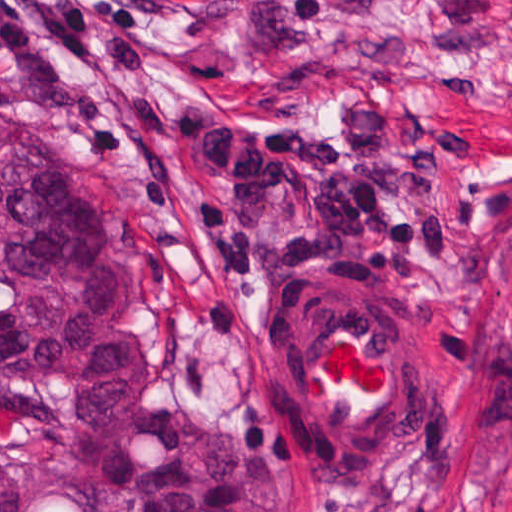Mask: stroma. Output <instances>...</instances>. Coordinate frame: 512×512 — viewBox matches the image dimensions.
Returning <instances> with one entry per match:
<instances>
[{"instance_id": "obj_1", "label": "stroma", "mask_w": 512, "mask_h": 512, "mask_svg": "<svg viewBox=\"0 0 512 512\" xmlns=\"http://www.w3.org/2000/svg\"><path fill=\"white\" fill-rule=\"evenodd\" d=\"M88 35L101 56L87 66L62 67L30 37L22 56L0 51V125L43 134L71 161L152 401L284 447L308 483L303 512H512V0H159L132 37ZM358 97H385L417 148L430 125L465 124L436 196L467 236L384 297L420 362L408 436L377 478L335 485L299 464L262 362L276 306L313 277L267 291L215 392L178 389L176 332L206 301L217 253L191 208L211 170L161 115L247 105L328 124Z\"/></svg>"}]
</instances>
